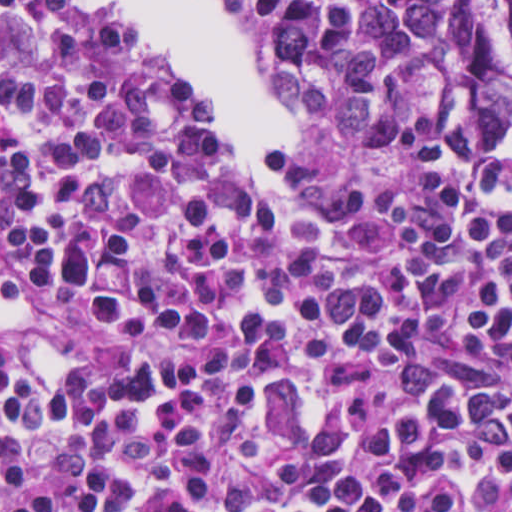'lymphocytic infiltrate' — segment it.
<instances>
[{
    "label": "lymphocytic infiltrate",
    "instance_id": "obj_1",
    "mask_svg": "<svg viewBox=\"0 0 512 512\" xmlns=\"http://www.w3.org/2000/svg\"><path fill=\"white\" fill-rule=\"evenodd\" d=\"M83 1L0 0V512H512V160L253 194Z\"/></svg>",
    "mask_w": 512,
    "mask_h": 512
}]
</instances>
